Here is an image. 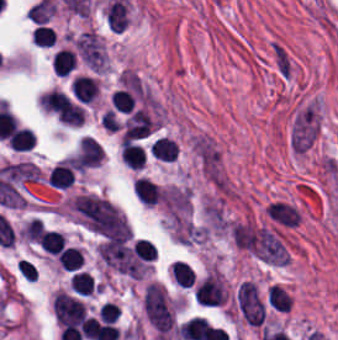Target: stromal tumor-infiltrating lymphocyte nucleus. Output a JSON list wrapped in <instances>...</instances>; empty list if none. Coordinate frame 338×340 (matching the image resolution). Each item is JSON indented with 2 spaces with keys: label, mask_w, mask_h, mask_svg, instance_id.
Here are the masks:
<instances>
[{
  "label": "stromal tumor-infiltrating lymphocyte nucleus",
  "mask_w": 338,
  "mask_h": 340,
  "mask_svg": "<svg viewBox=\"0 0 338 340\" xmlns=\"http://www.w3.org/2000/svg\"><path fill=\"white\" fill-rule=\"evenodd\" d=\"M71 90L79 102L89 104L98 94V83L89 76L76 74L71 80Z\"/></svg>",
  "instance_id": "stromal-tumor-infiltrating-lymphocyte-nucleus-1"
},
{
  "label": "stromal tumor-infiltrating lymphocyte nucleus",
  "mask_w": 338,
  "mask_h": 340,
  "mask_svg": "<svg viewBox=\"0 0 338 340\" xmlns=\"http://www.w3.org/2000/svg\"><path fill=\"white\" fill-rule=\"evenodd\" d=\"M132 189L141 204L153 206L161 200V189L149 178L136 177Z\"/></svg>",
  "instance_id": "stromal-tumor-infiltrating-lymphocyte-nucleus-2"
},
{
  "label": "stromal tumor-infiltrating lymphocyte nucleus",
  "mask_w": 338,
  "mask_h": 340,
  "mask_svg": "<svg viewBox=\"0 0 338 340\" xmlns=\"http://www.w3.org/2000/svg\"><path fill=\"white\" fill-rule=\"evenodd\" d=\"M47 179L52 188L67 189L74 181V172L66 162H58L48 173Z\"/></svg>",
  "instance_id": "stromal-tumor-infiltrating-lymphocyte-nucleus-3"
},
{
  "label": "stromal tumor-infiltrating lymphocyte nucleus",
  "mask_w": 338,
  "mask_h": 340,
  "mask_svg": "<svg viewBox=\"0 0 338 340\" xmlns=\"http://www.w3.org/2000/svg\"><path fill=\"white\" fill-rule=\"evenodd\" d=\"M8 143L13 151H30L36 143V136L27 127L18 126L11 134Z\"/></svg>",
  "instance_id": "stromal-tumor-infiltrating-lymphocyte-nucleus-4"
},
{
  "label": "stromal tumor-infiltrating lymphocyte nucleus",
  "mask_w": 338,
  "mask_h": 340,
  "mask_svg": "<svg viewBox=\"0 0 338 340\" xmlns=\"http://www.w3.org/2000/svg\"><path fill=\"white\" fill-rule=\"evenodd\" d=\"M77 64L74 52L68 48H61L53 55L51 66L52 70L61 76H67Z\"/></svg>",
  "instance_id": "stromal-tumor-infiltrating-lymphocyte-nucleus-5"
},
{
  "label": "stromal tumor-infiltrating lymphocyte nucleus",
  "mask_w": 338,
  "mask_h": 340,
  "mask_svg": "<svg viewBox=\"0 0 338 340\" xmlns=\"http://www.w3.org/2000/svg\"><path fill=\"white\" fill-rule=\"evenodd\" d=\"M151 156L166 160L175 159L178 145L169 138L157 137L150 149Z\"/></svg>",
  "instance_id": "stromal-tumor-infiltrating-lymphocyte-nucleus-6"
},
{
  "label": "stromal tumor-infiltrating lymphocyte nucleus",
  "mask_w": 338,
  "mask_h": 340,
  "mask_svg": "<svg viewBox=\"0 0 338 340\" xmlns=\"http://www.w3.org/2000/svg\"><path fill=\"white\" fill-rule=\"evenodd\" d=\"M58 264L68 270H77L83 261V252L77 247H63L56 257Z\"/></svg>",
  "instance_id": "stromal-tumor-infiltrating-lymphocyte-nucleus-7"
},
{
  "label": "stromal tumor-infiltrating lymphocyte nucleus",
  "mask_w": 338,
  "mask_h": 340,
  "mask_svg": "<svg viewBox=\"0 0 338 340\" xmlns=\"http://www.w3.org/2000/svg\"><path fill=\"white\" fill-rule=\"evenodd\" d=\"M267 304L274 311H289L291 304L289 295L277 285H269L267 288Z\"/></svg>",
  "instance_id": "stromal-tumor-infiltrating-lymphocyte-nucleus-8"
},
{
  "label": "stromal tumor-infiltrating lymphocyte nucleus",
  "mask_w": 338,
  "mask_h": 340,
  "mask_svg": "<svg viewBox=\"0 0 338 340\" xmlns=\"http://www.w3.org/2000/svg\"><path fill=\"white\" fill-rule=\"evenodd\" d=\"M71 286L76 293L91 295L95 290L96 282L88 272L77 270L71 275Z\"/></svg>",
  "instance_id": "stromal-tumor-infiltrating-lymphocyte-nucleus-9"
},
{
  "label": "stromal tumor-infiltrating lymphocyte nucleus",
  "mask_w": 338,
  "mask_h": 340,
  "mask_svg": "<svg viewBox=\"0 0 338 340\" xmlns=\"http://www.w3.org/2000/svg\"><path fill=\"white\" fill-rule=\"evenodd\" d=\"M172 274L179 285L190 287L195 281V277L190 265L182 259H174L172 267Z\"/></svg>",
  "instance_id": "stromal-tumor-infiltrating-lymphocyte-nucleus-10"
},
{
  "label": "stromal tumor-infiltrating lymphocyte nucleus",
  "mask_w": 338,
  "mask_h": 340,
  "mask_svg": "<svg viewBox=\"0 0 338 340\" xmlns=\"http://www.w3.org/2000/svg\"><path fill=\"white\" fill-rule=\"evenodd\" d=\"M65 239L66 237L61 232L45 230L39 244L45 252L57 255Z\"/></svg>",
  "instance_id": "stromal-tumor-infiltrating-lymphocyte-nucleus-11"
},
{
  "label": "stromal tumor-infiltrating lymphocyte nucleus",
  "mask_w": 338,
  "mask_h": 340,
  "mask_svg": "<svg viewBox=\"0 0 338 340\" xmlns=\"http://www.w3.org/2000/svg\"><path fill=\"white\" fill-rule=\"evenodd\" d=\"M132 247L136 257L150 260L156 257V252L152 242L145 238H137L134 242H132Z\"/></svg>",
  "instance_id": "stromal-tumor-infiltrating-lymphocyte-nucleus-12"
},
{
  "label": "stromal tumor-infiltrating lymphocyte nucleus",
  "mask_w": 338,
  "mask_h": 340,
  "mask_svg": "<svg viewBox=\"0 0 338 340\" xmlns=\"http://www.w3.org/2000/svg\"><path fill=\"white\" fill-rule=\"evenodd\" d=\"M34 44L41 46H52L53 32L48 26L36 25L32 30Z\"/></svg>",
  "instance_id": "stromal-tumor-infiltrating-lymphocyte-nucleus-13"
},
{
  "label": "stromal tumor-infiltrating lymphocyte nucleus",
  "mask_w": 338,
  "mask_h": 340,
  "mask_svg": "<svg viewBox=\"0 0 338 340\" xmlns=\"http://www.w3.org/2000/svg\"><path fill=\"white\" fill-rule=\"evenodd\" d=\"M289 258H287L282 264L288 263Z\"/></svg>",
  "instance_id": "stromal-tumor-infiltrating-lymphocyte-nucleus-14"
}]
</instances>
